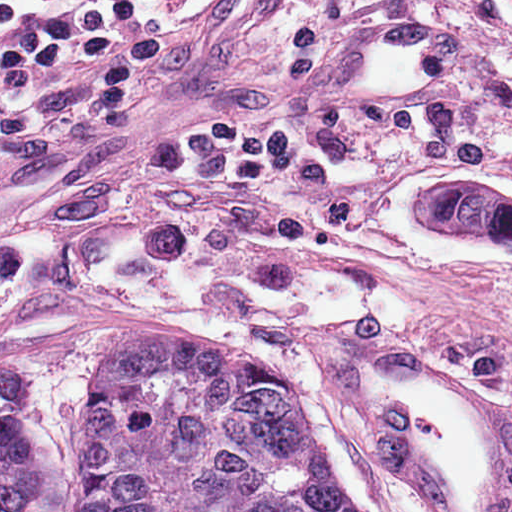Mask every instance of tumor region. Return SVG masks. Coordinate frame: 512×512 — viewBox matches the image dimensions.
Returning <instances> with one entry per match:
<instances>
[{"label":"tumor region","instance_id":"obj_1","mask_svg":"<svg viewBox=\"0 0 512 512\" xmlns=\"http://www.w3.org/2000/svg\"><path fill=\"white\" fill-rule=\"evenodd\" d=\"M418 195L434 226L473 232L448 176ZM130 337L93 411L85 512H373L328 470L308 402L289 385ZM34 398L35 379L1 363L0 512H24L35 481Z\"/></svg>","mask_w":512,"mask_h":512}]
</instances>
